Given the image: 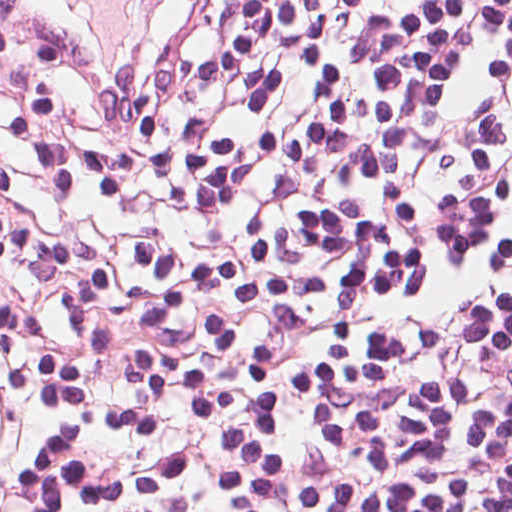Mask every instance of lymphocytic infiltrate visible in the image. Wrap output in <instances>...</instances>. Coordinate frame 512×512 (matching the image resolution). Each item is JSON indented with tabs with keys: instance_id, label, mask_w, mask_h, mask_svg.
<instances>
[{
	"instance_id": "f902f5d3",
	"label": "lymphocytic infiltrate",
	"mask_w": 512,
	"mask_h": 512,
	"mask_svg": "<svg viewBox=\"0 0 512 512\" xmlns=\"http://www.w3.org/2000/svg\"><path fill=\"white\" fill-rule=\"evenodd\" d=\"M0 512H512V0L92 11Z\"/></svg>"
}]
</instances>
